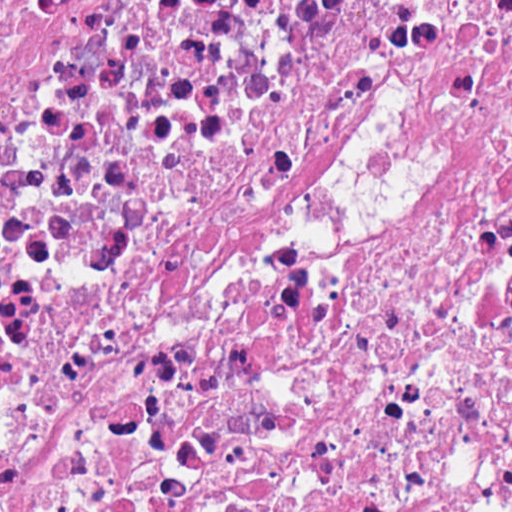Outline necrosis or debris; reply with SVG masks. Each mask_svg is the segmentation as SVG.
Masks as SVG:
<instances>
[{"instance_id":"necrosis-or-debris-1","label":"necrosis or debris","mask_w":512,"mask_h":512,"mask_svg":"<svg viewBox=\"0 0 512 512\" xmlns=\"http://www.w3.org/2000/svg\"><path fill=\"white\" fill-rule=\"evenodd\" d=\"M0 512H512V0H0Z\"/></svg>"}]
</instances>
